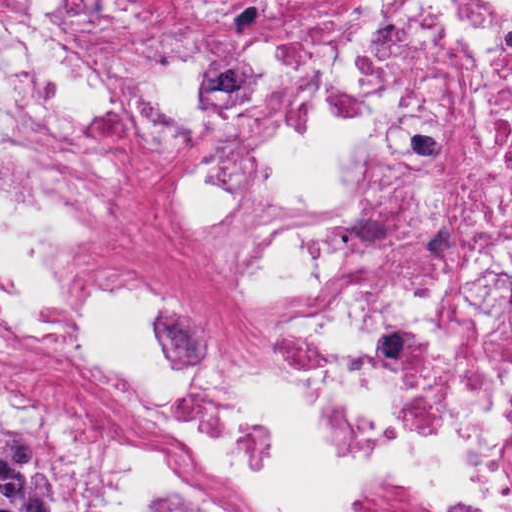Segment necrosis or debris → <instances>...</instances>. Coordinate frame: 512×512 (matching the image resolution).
<instances>
[{
  "label": "necrosis or debris",
  "instance_id": "necrosis-or-debris-1",
  "mask_svg": "<svg viewBox=\"0 0 512 512\" xmlns=\"http://www.w3.org/2000/svg\"><path fill=\"white\" fill-rule=\"evenodd\" d=\"M0 399L87 512H512V0H0Z\"/></svg>",
  "mask_w": 512,
  "mask_h": 512
}]
</instances>
